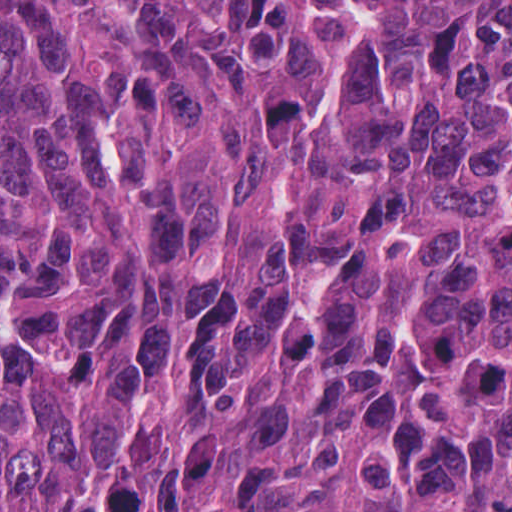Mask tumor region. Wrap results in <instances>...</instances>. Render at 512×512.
I'll return each mask as SVG.
<instances>
[{"mask_svg": "<svg viewBox=\"0 0 512 512\" xmlns=\"http://www.w3.org/2000/svg\"><path fill=\"white\" fill-rule=\"evenodd\" d=\"M0 512H512V0H0Z\"/></svg>", "mask_w": 512, "mask_h": 512, "instance_id": "e687c5a6", "label": "tumor region"}]
</instances>
